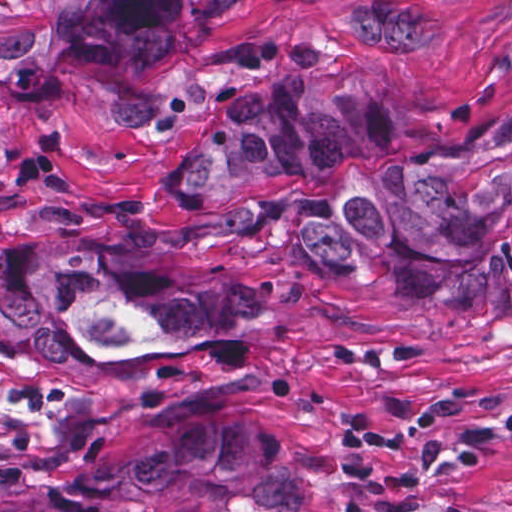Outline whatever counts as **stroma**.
<instances>
[{"mask_svg":"<svg viewBox=\"0 0 512 512\" xmlns=\"http://www.w3.org/2000/svg\"><path fill=\"white\" fill-rule=\"evenodd\" d=\"M366 74L414 137L512 107V0H234L174 57L1 77L0 512L163 434L245 426L302 474L300 512H512V320L312 249L307 178L246 200L177 174L243 90ZM82 227L214 264L281 309L271 339L90 363L1 319V241Z\"/></svg>","mask_w":512,"mask_h":512,"instance_id":"35a3bbf8","label":"stroma"}]
</instances>
